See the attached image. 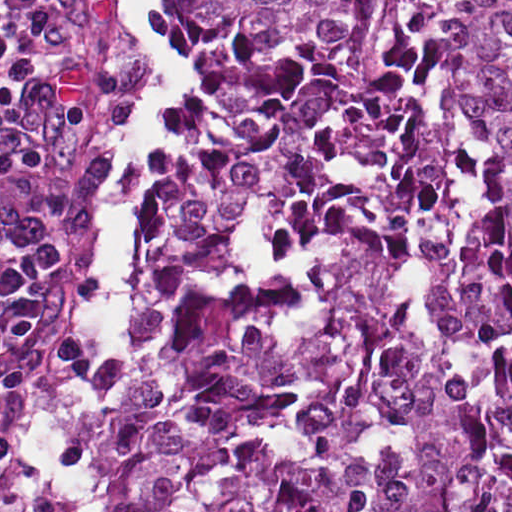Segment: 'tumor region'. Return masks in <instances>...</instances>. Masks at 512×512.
I'll return each instance as SVG.
<instances>
[{
	"label": "tumor region",
	"instance_id": "1",
	"mask_svg": "<svg viewBox=\"0 0 512 512\" xmlns=\"http://www.w3.org/2000/svg\"><path fill=\"white\" fill-rule=\"evenodd\" d=\"M170 41L204 120L110 512H512V0H172Z\"/></svg>",
	"mask_w": 512,
	"mask_h": 512
}]
</instances>
